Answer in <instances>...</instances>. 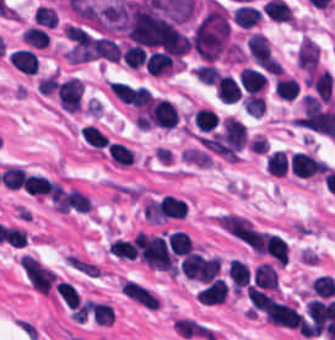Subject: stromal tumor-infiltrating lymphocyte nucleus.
Listing matches in <instances>:
<instances>
[{"label": "stromal tumor-infiltrating lymphocyte nucleus", "instance_id": "obj_1", "mask_svg": "<svg viewBox=\"0 0 335 340\" xmlns=\"http://www.w3.org/2000/svg\"><path fill=\"white\" fill-rule=\"evenodd\" d=\"M247 125L234 115H226L222 121L218 149L225 158H237L246 145Z\"/></svg>", "mask_w": 335, "mask_h": 340}, {"label": "stromal tumor-infiltrating lymphocyte nucleus", "instance_id": "obj_2", "mask_svg": "<svg viewBox=\"0 0 335 340\" xmlns=\"http://www.w3.org/2000/svg\"><path fill=\"white\" fill-rule=\"evenodd\" d=\"M84 87L78 78H70L57 85V100L66 112H79L82 106Z\"/></svg>", "mask_w": 335, "mask_h": 340}, {"label": "stromal tumor-infiltrating lymphocyte nucleus", "instance_id": "obj_3", "mask_svg": "<svg viewBox=\"0 0 335 340\" xmlns=\"http://www.w3.org/2000/svg\"><path fill=\"white\" fill-rule=\"evenodd\" d=\"M178 123L176 105L169 100L154 98L149 108V124L156 127L173 128Z\"/></svg>", "mask_w": 335, "mask_h": 340}, {"label": "stromal tumor-infiltrating lymphocyte nucleus", "instance_id": "obj_4", "mask_svg": "<svg viewBox=\"0 0 335 340\" xmlns=\"http://www.w3.org/2000/svg\"><path fill=\"white\" fill-rule=\"evenodd\" d=\"M289 165L293 175L309 177L324 171L328 165L315 155L303 151H296L289 158Z\"/></svg>", "mask_w": 335, "mask_h": 340}, {"label": "stromal tumor-infiltrating lymphocyte nucleus", "instance_id": "obj_5", "mask_svg": "<svg viewBox=\"0 0 335 340\" xmlns=\"http://www.w3.org/2000/svg\"><path fill=\"white\" fill-rule=\"evenodd\" d=\"M320 49L309 37H301L295 64L306 73H313L319 59Z\"/></svg>", "mask_w": 335, "mask_h": 340}, {"label": "stromal tumor-infiltrating lymphocyte nucleus", "instance_id": "obj_6", "mask_svg": "<svg viewBox=\"0 0 335 340\" xmlns=\"http://www.w3.org/2000/svg\"><path fill=\"white\" fill-rule=\"evenodd\" d=\"M229 287L225 278L215 277L197 292L199 303L213 305L225 303Z\"/></svg>", "mask_w": 335, "mask_h": 340}, {"label": "stromal tumor-infiltrating lymphocyte nucleus", "instance_id": "obj_7", "mask_svg": "<svg viewBox=\"0 0 335 340\" xmlns=\"http://www.w3.org/2000/svg\"><path fill=\"white\" fill-rule=\"evenodd\" d=\"M250 285L260 289L277 290L278 273L272 263L260 262L255 266Z\"/></svg>", "mask_w": 335, "mask_h": 340}, {"label": "stromal tumor-infiltrating lymphocyte nucleus", "instance_id": "obj_8", "mask_svg": "<svg viewBox=\"0 0 335 340\" xmlns=\"http://www.w3.org/2000/svg\"><path fill=\"white\" fill-rule=\"evenodd\" d=\"M246 49L256 64H269L272 61V52L267 39L259 34L252 33L245 41Z\"/></svg>", "mask_w": 335, "mask_h": 340}, {"label": "stromal tumor-infiltrating lymphocyte nucleus", "instance_id": "obj_9", "mask_svg": "<svg viewBox=\"0 0 335 340\" xmlns=\"http://www.w3.org/2000/svg\"><path fill=\"white\" fill-rule=\"evenodd\" d=\"M228 271L234 293L241 295L250 284L251 275L248 265L234 257L229 261Z\"/></svg>", "mask_w": 335, "mask_h": 340}, {"label": "stromal tumor-infiltrating lymphocyte nucleus", "instance_id": "obj_10", "mask_svg": "<svg viewBox=\"0 0 335 340\" xmlns=\"http://www.w3.org/2000/svg\"><path fill=\"white\" fill-rule=\"evenodd\" d=\"M107 156L113 164L132 165L137 159L132 146L118 139H111L107 147Z\"/></svg>", "mask_w": 335, "mask_h": 340}, {"label": "stromal tumor-infiltrating lymphocyte nucleus", "instance_id": "obj_11", "mask_svg": "<svg viewBox=\"0 0 335 340\" xmlns=\"http://www.w3.org/2000/svg\"><path fill=\"white\" fill-rule=\"evenodd\" d=\"M147 73L154 77H170L173 71L172 59L166 52L153 51L145 58Z\"/></svg>", "mask_w": 335, "mask_h": 340}, {"label": "stromal tumor-infiltrating lymphocyte nucleus", "instance_id": "obj_12", "mask_svg": "<svg viewBox=\"0 0 335 340\" xmlns=\"http://www.w3.org/2000/svg\"><path fill=\"white\" fill-rule=\"evenodd\" d=\"M306 81L321 99L332 102L333 77L328 69L310 74Z\"/></svg>", "mask_w": 335, "mask_h": 340}, {"label": "stromal tumor-infiltrating lymphocyte nucleus", "instance_id": "obj_13", "mask_svg": "<svg viewBox=\"0 0 335 340\" xmlns=\"http://www.w3.org/2000/svg\"><path fill=\"white\" fill-rule=\"evenodd\" d=\"M238 79L245 93H251L264 89L266 77L259 70L251 66H244L238 73Z\"/></svg>", "mask_w": 335, "mask_h": 340}, {"label": "stromal tumor-infiltrating lymphocyte nucleus", "instance_id": "obj_14", "mask_svg": "<svg viewBox=\"0 0 335 340\" xmlns=\"http://www.w3.org/2000/svg\"><path fill=\"white\" fill-rule=\"evenodd\" d=\"M265 251L278 266H285L288 252L284 240L278 234H265L263 238Z\"/></svg>", "mask_w": 335, "mask_h": 340}, {"label": "stromal tumor-infiltrating lymphocyte nucleus", "instance_id": "obj_15", "mask_svg": "<svg viewBox=\"0 0 335 340\" xmlns=\"http://www.w3.org/2000/svg\"><path fill=\"white\" fill-rule=\"evenodd\" d=\"M8 61L26 75H35L38 70L37 55L33 51L19 49L8 57Z\"/></svg>", "mask_w": 335, "mask_h": 340}, {"label": "stromal tumor-infiltrating lymphocyte nucleus", "instance_id": "obj_16", "mask_svg": "<svg viewBox=\"0 0 335 340\" xmlns=\"http://www.w3.org/2000/svg\"><path fill=\"white\" fill-rule=\"evenodd\" d=\"M215 93L224 102L232 103L239 99L241 90L237 80L230 74L219 75Z\"/></svg>", "mask_w": 335, "mask_h": 340}, {"label": "stromal tumor-infiltrating lymphocyte nucleus", "instance_id": "obj_17", "mask_svg": "<svg viewBox=\"0 0 335 340\" xmlns=\"http://www.w3.org/2000/svg\"><path fill=\"white\" fill-rule=\"evenodd\" d=\"M23 187L26 193L43 197L52 194L54 184L40 174H26Z\"/></svg>", "mask_w": 335, "mask_h": 340}, {"label": "stromal tumor-infiltrating lymphocyte nucleus", "instance_id": "obj_18", "mask_svg": "<svg viewBox=\"0 0 335 340\" xmlns=\"http://www.w3.org/2000/svg\"><path fill=\"white\" fill-rule=\"evenodd\" d=\"M168 246L177 257L189 255L193 250V244L187 233L177 229L168 235Z\"/></svg>", "mask_w": 335, "mask_h": 340}, {"label": "stromal tumor-infiltrating lymphocyte nucleus", "instance_id": "obj_19", "mask_svg": "<svg viewBox=\"0 0 335 340\" xmlns=\"http://www.w3.org/2000/svg\"><path fill=\"white\" fill-rule=\"evenodd\" d=\"M192 118L198 131L209 132L214 129L219 122L216 112L207 106H199L192 115Z\"/></svg>", "mask_w": 335, "mask_h": 340}, {"label": "stromal tumor-infiltrating lymphocyte nucleus", "instance_id": "obj_20", "mask_svg": "<svg viewBox=\"0 0 335 340\" xmlns=\"http://www.w3.org/2000/svg\"><path fill=\"white\" fill-rule=\"evenodd\" d=\"M289 166L288 155L283 150H275L269 153L266 161V170L274 176L285 175Z\"/></svg>", "mask_w": 335, "mask_h": 340}, {"label": "stromal tumor-infiltrating lymphocyte nucleus", "instance_id": "obj_21", "mask_svg": "<svg viewBox=\"0 0 335 340\" xmlns=\"http://www.w3.org/2000/svg\"><path fill=\"white\" fill-rule=\"evenodd\" d=\"M107 252L126 260H134L137 257V249L129 239H113L109 243Z\"/></svg>", "mask_w": 335, "mask_h": 340}, {"label": "stromal tumor-infiltrating lymphocyte nucleus", "instance_id": "obj_22", "mask_svg": "<svg viewBox=\"0 0 335 340\" xmlns=\"http://www.w3.org/2000/svg\"><path fill=\"white\" fill-rule=\"evenodd\" d=\"M80 137L93 148H106L107 137L94 125L86 124L79 131Z\"/></svg>", "mask_w": 335, "mask_h": 340}, {"label": "stromal tumor-infiltrating lymphocyte nucleus", "instance_id": "obj_23", "mask_svg": "<svg viewBox=\"0 0 335 340\" xmlns=\"http://www.w3.org/2000/svg\"><path fill=\"white\" fill-rule=\"evenodd\" d=\"M273 89L279 99L291 101L298 93V86L291 77H278L274 80Z\"/></svg>", "mask_w": 335, "mask_h": 340}, {"label": "stromal tumor-infiltrating lymphocyte nucleus", "instance_id": "obj_24", "mask_svg": "<svg viewBox=\"0 0 335 340\" xmlns=\"http://www.w3.org/2000/svg\"><path fill=\"white\" fill-rule=\"evenodd\" d=\"M20 36L31 47L46 48L49 43L48 33L33 25L26 28Z\"/></svg>", "mask_w": 335, "mask_h": 340}, {"label": "stromal tumor-infiltrating lymphocyte nucleus", "instance_id": "obj_25", "mask_svg": "<svg viewBox=\"0 0 335 340\" xmlns=\"http://www.w3.org/2000/svg\"><path fill=\"white\" fill-rule=\"evenodd\" d=\"M26 171L16 165H9L1 171L4 187L8 190H20Z\"/></svg>", "mask_w": 335, "mask_h": 340}, {"label": "stromal tumor-infiltrating lymphocyte nucleus", "instance_id": "obj_26", "mask_svg": "<svg viewBox=\"0 0 335 340\" xmlns=\"http://www.w3.org/2000/svg\"><path fill=\"white\" fill-rule=\"evenodd\" d=\"M310 284L316 296L328 298L335 293V280L327 273H320Z\"/></svg>", "mask_w": 335, "mask_h": 340}, {"label": "stromal tumor-infiltrating lymphocyte nucleus", "instance_id": "obj_27", "mask_svg": "<svg viewBox=\"0 0 335 340\" xmlns=\"http://www.w3.org/2000/svg\"><path fill=\"white\" fill-rule=\"evenodd\" d=\"M241 103L247 115L258 117L266 107L262 94L256 92H249L242 98Z\"/></svg>", "mask_w": 335, "mask_h": 340}, {"label": "stromal tumor-infiltrating lymphocyte nucleus", "instance_id": "obj_28", "mask_svg": "<svg viewBox=\"0 0 335 340\" xmlns=\"http://www.w3.org/2000/svg\"><path fill=\"white\" fill-rule=\"evenodd\" d=\"M58 296L67 307L73 309L80 301L78 290L67 281H59Z\"/></svg>", "mask_w": 335, "mask_h": 340}, {"label": "stromal tumor-infiltrating lymphocyte nucleus", "instance_id": "obj_29", "mask_svg": "<svg viewBox=\"0 0 335 340\" xmlns=\"http://www.w3.org/2000/svg\"><path fill=\"white\" fill-rule=\"evenodd\" d=\"M124 61L128 69H137L144 64V50L134 45H127L122 49Z\"/></svg>", "mask_w": 335, "mask_h": 340}, {"label": "stromal tumor-infiltrating lymphocyte nucleus", "instance_id": "obj_30", "mask_svg": "<svg viewBox=\"0 0 335 340\" xmlns=\"http://www.w3.org/2000/svg\"><path fill=\"white\" fill-rule=\"evenodd\" d=\"M193 73L202 83L214 85L219 75V69L207 62L196 66Z\"/></svg>", "mask_w": 335, "mask_h": 340}, {"label": "stromal tumor-infiltrating lymphocyte nucleus", "instance_id": "obj_31", "mask_svg": "<svg viewBox=\"0 0 335 340\" xmlns=\"http://www.w3.org/2000/svg\"><path fill=\"white\" fill-rule=\"evenodd\" d=\"M113 318V312L110 306L102 302H95L93 321L96 325L110 326Z\"/></svg>", "mask_w": 335, "mask_h": 340}, {"label": "stromal tumor-infiltrating lymphocyte nucleus", "instance_id": "obj_32", "mask_svg": "<svg viewBox=\"0 0 335 340\" xmlns=\"http://www.w3.org/2000/svg\"><path fill=\"white\" fill-rule=\"evenodd\" d=\"M58 85L57 74H49L41 77L37 86L41 95H51L55 92Z\"/></svg>", "mask_w": 335, "mask_h": 340}]
</instances>
